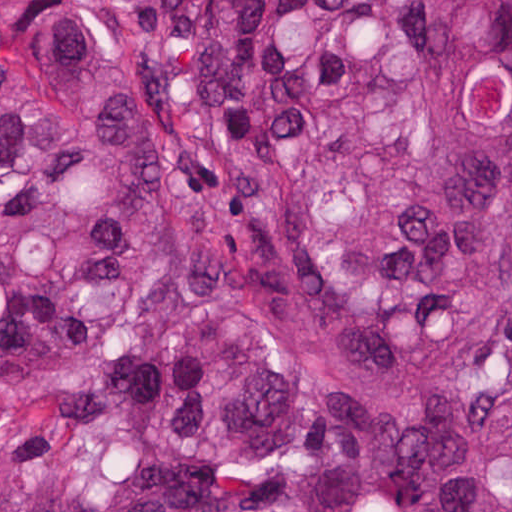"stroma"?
<instances>
[{"label": "stroma", "mask_w": 512, "mask_h": 512, "mask_svg": "<svg viewBox=\"0 0 512 512\" xmlns=\"http://www.w3.org/2000/svg\"><path fill=\"white\" fill-rule=\"evenodd\" d=\"M61 3L106 5L122 25L139 34H155L169 12L168 0H0V35L9 25L46 13Z\"/></svg>", "instance_id": "35a3bbf8"}]
</instances>
